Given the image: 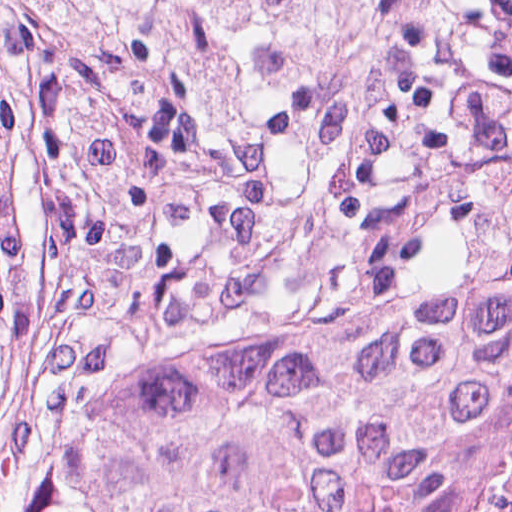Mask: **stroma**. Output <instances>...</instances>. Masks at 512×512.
Segmentation results:
<instances>
[{"instance_id":"stroma-1","label":"stroma","mask_w":512,"mask_h":512,"mask_svg":"<svg viewBox=\"0 0 512 512\" xmlns=\"http://www.w3.org/2000/svg\"><path fill=\"white\" fill-rule=\"evenodd\" d=\"M0 177L28 285L0 512H33L107 399L187 338L512 265V0H314L310 47L232 125L176 65L95 57L0 0ZM511 373L449 423L437 479Z\"/></svg>"}]
</instances>
